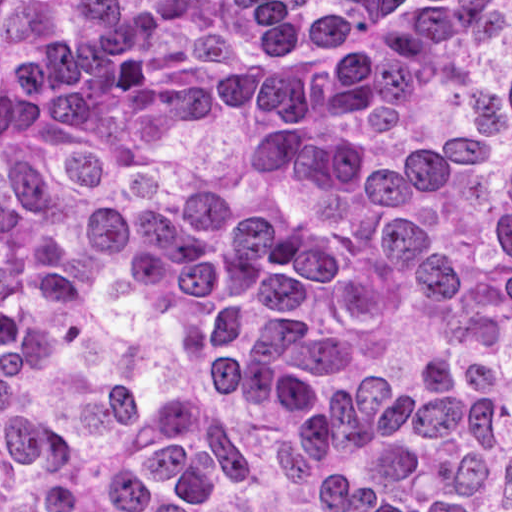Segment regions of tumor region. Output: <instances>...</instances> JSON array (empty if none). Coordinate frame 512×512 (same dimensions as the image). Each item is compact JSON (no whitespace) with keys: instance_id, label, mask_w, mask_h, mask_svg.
<instances>
[{"instance_id":"e687c5a6","label":"tumor region","mask_w":512,"mask_h":512,"mask_svg":"<svg viewBox=\"0 0 512 512\" xmlns=\"http://www.w3.org/2000/svg\"><path fill=\"white\" fill-rule=\"evenodd\" d=\"M0 512H512V0H0Z\"/></svg>"}]
</instances>
